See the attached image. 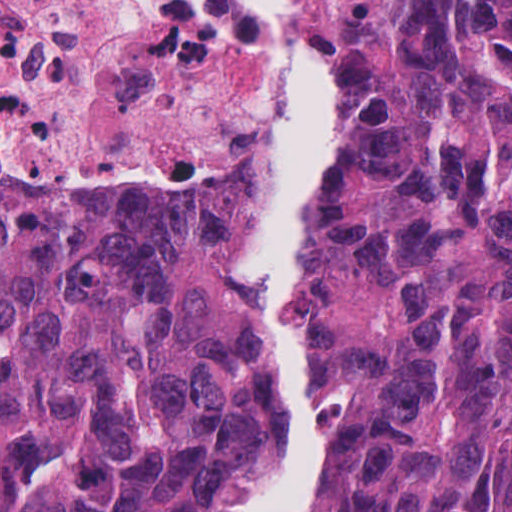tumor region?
I'll return each instance as SVG.
<instances>
[{
  "instance_id": "e687c5a6",
  "label": "tumor region",
  "mask_w": 512,
  "mask_h": 512,
  "mask_svg": "<svg viewBox=\"0 0 512 512\" xmlns=\"http://www.w3.org/2000/svg\"><path fill=\"white\" fill-rule=\"evenodd\" d=\"M217 186L0 185V512H215L281 448L240 246L280 155ZM342 168L303 237L339 425L315 512H512V0H315Z\"/></svg>"
}]
</instances>
